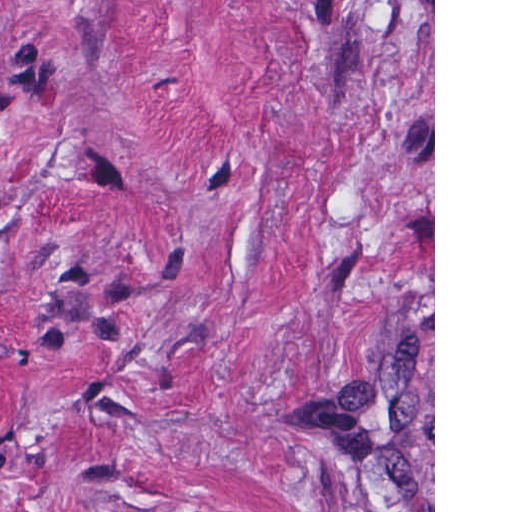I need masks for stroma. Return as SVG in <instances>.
Instances as JSON below:
<instances>
[{"label":"stroma","mask_w":512,"mask_h":512,"mask_svg":"<svg viewBox=\"0 0 512 512\" xmlns=\"http://www.w3.org/2000/svg\"><path fill=\"white\" fill-rule=\"evenodd\" d=\"M0 512H435V0H0Z\"/></svg>","instance_id":"stroma-1"}]
</instances>
